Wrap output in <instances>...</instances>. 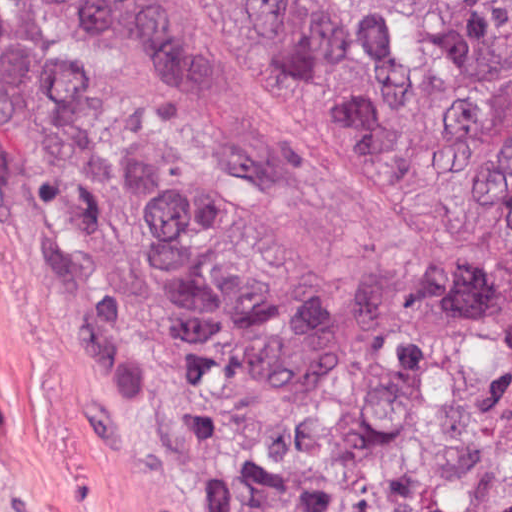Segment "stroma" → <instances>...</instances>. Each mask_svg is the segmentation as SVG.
<instances>
[{"label": "stroma", "instance_id": "35a3bbf8", "mask_svg": "<svg viewBox=\"0 0 512 512\" xmlns=\"http://www.w3.org/2000/svg\"><path fill=\"white\" fill-rule=\"evenodd\" d=\"M0 512H241L207 347L97 67L1 10Z\"/></svg>", "mask_w": 512, "mask_h": 512}]
</instances>
